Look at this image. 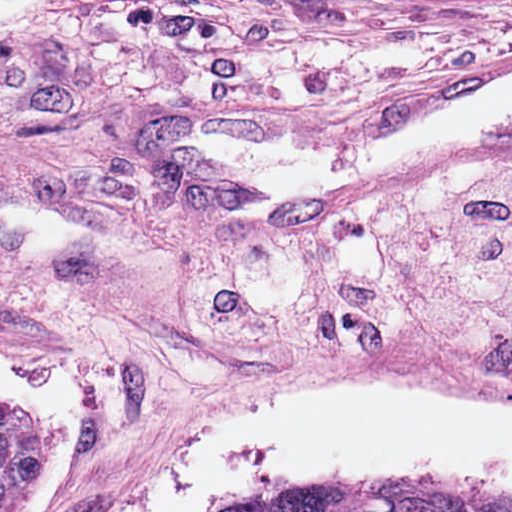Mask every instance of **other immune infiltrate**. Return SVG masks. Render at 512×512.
<instances>
[{
  "instance_id": "1",
  "label": "other immune infiltrate",
  "mask_w": 512,
  "mask_h": 512,
  "mask_svg": "<svg viewBox=\"0 0 512 512\" xmlns=\"http://www.w3.org/2000/svg\"><path fill=\"white\" fill-rule=\"evenodd\" d=\"M142 295L223 347L297 341L361 358L424 335L465 360H512V151Z\"/></svg>"
}]
</instances>
